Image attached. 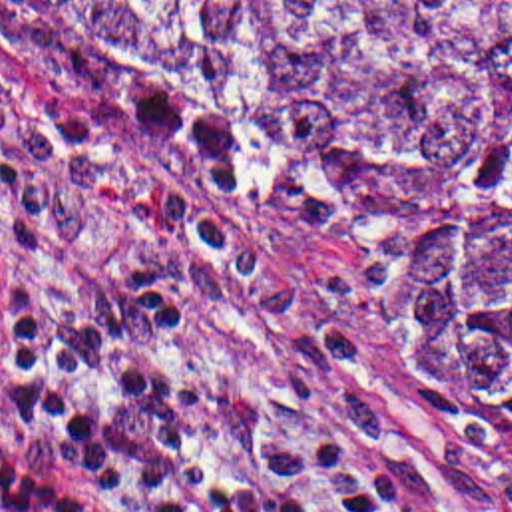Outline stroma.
I'll return each mask as SVG.
<instances>
[{"instance_id":"obj_1","label":"stroma","mask_w":512,"mask_h":512,"mask_svg":"<svg viewBox=\"0 0 512 512\" xmlns=\"http://www.w3.org/2000/svg\"><path fill=\"white\" fill-rule=\"evenodd\" d=\"M153 273L185 350L364 440L392 512H512V466L480 476L372 314L312 259L93 153L50 77L0 36V293L22 316L79 318Z\"/></svg>"}]
</instances>
